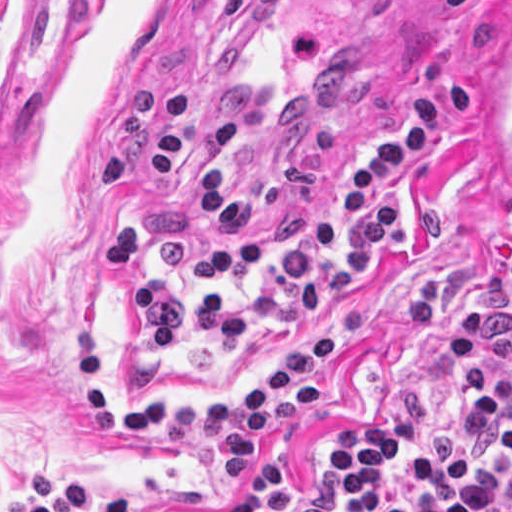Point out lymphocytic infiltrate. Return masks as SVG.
I'll return each instance as SVG.
<instances>
[{
  "instance_id": "obj_1",
  "label": "lymphocytic infiltrate",
  "mask_w": 512,
  "mask_h": 512,
  "mask_svg": "<svg viewBox=\"0 0 512 512\" xmlns=\"http://www.w3.org/2000/svg\"><path fill=\"white\" fill-rule=\"evenodd\" d=\"M473 94L443 79L407 106L401 128L342 181L331 209L293 210L279 181L235 185L239 126L217 122L200 173V214L227 236H245L194 256L199 284L261 283L253 297L193 291L154 251L150 229L130 223L103 232L102 254L136 304L139 343L168 353L215 352L300 319L321 329L297 343L262 380L223 402L111 399L94 338L77 335L84 424L95 433H155L179 463L246 476L252 445L326 398L320 378L345 340L374 325V306H334L369 274L378 255L404 243L396 181L434 141L468 121ZM456 411L424 416L403 393L387 396L373 422L337 435L328 471L285 472L255 485L252 512H512V219L483 257L453 313ZM27 512H138L137 493L106 503L87 482L49 471L26 476Z\"/></svg>"
}]
</instances>
